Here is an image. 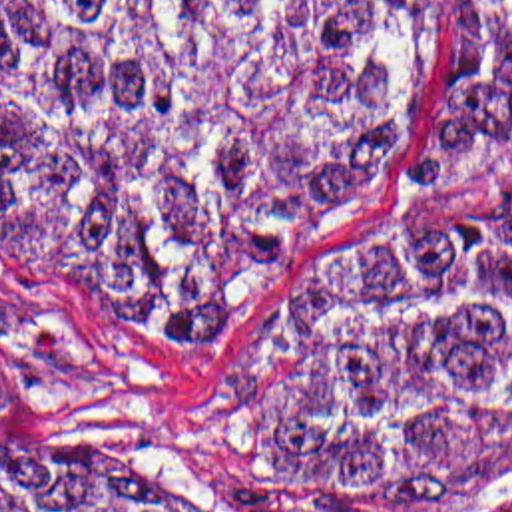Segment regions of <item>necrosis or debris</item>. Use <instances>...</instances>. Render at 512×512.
<instances>
[{"mask_svg": "<svg viewBox=\"0 0 512 512\" xmlns=\"http://www.w3.org/2000/svg\"><path fill=\"white\" fill-rule=\"evenodd\" d=\"M476 512H512V476L498 488V492Z\"/></svg>", "mask_w": 512, "mask_h": 512, "instance_id": "necrosis-or-debris-1", "label": "necrosis or debris"}]
</instances>
